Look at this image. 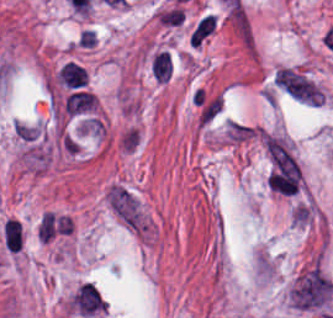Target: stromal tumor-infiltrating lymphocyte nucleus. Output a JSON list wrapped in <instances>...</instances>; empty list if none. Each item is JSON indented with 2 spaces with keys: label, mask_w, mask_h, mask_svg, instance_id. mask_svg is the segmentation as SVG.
Segmentation results:
<instances>
[{
  "label": "stromal tumor-infiltrating lymphocyte nucleus",
  "mask_w": 333,
  "mask_h": 318,
  "mask_svg": "<svg viewBox=\"0 0 333 318\" xmlns=\"http://www.w3.org/2000/svg\"><path fill=\"white\" fill-rule=\"evenodd\" d=\"M97 105V98L94 91L74 89L63 102L64 112L77 114L92 110Z\"/></svg>",
  "instance_id": "bc302bb0"
},
{
  "label": "stromal tumor-infiltrating lymphocyte nucleus",
  "mask_w": 333,
  "mask_h": 318,
  "mask_svg": "<svg viewBox=\"0 0 333 318\" xmlns=\"http://www.w3.org/2000/svg\"><path fill=\"white\" fill-rule=\"evenodd\" d=\"M149 69L153 79L168 81L173 72V62L170 52L158 49L149 60Z\"/></svg>",
  "instance_id": "52c7bb5b"
},
{
  "label": "stromal tumor-infiltrating lymphocyte nucleus",
  "mask_w": 333,
  "mask_h": 318,
  "mask_svg": "<svg viewBox=\"0 0 333 318\" xmlns=\"http://www.w3.org/2000/svg\"><path fill=\"white\" fill-rule=\"evenodd\" d=\"M58 76L63 83L71 87H79L88 82V73L84 65L75 60H68L58 70Z\"/></svg>",
  "instance_id": "3290ff9b"
}]
</instances>
